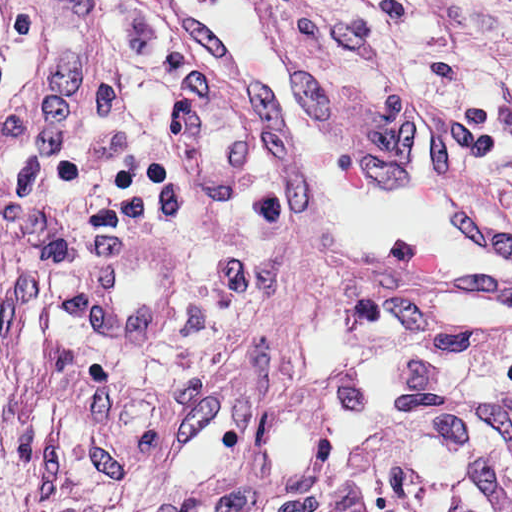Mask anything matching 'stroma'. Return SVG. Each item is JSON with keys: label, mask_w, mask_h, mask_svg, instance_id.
I'll return each mask as SVG.
<instances>
[{"label": "stroma", "mask_w": 512, "mask_h": 512, "mask_svg": "<svg viewBox=\"0 0 512 512\" xmlns=\"http://www.w3.org/2000/svg\"><path fill=\"white\" fill-rule=\"evenodd\" d=\"M352 151L406 95L512 215L487 0H278ZM512 388V311L349 291L150 0H0V512H245L387 391Z\"/></svg>", "instance_id": "35a3bbf8"}]
</instances>
